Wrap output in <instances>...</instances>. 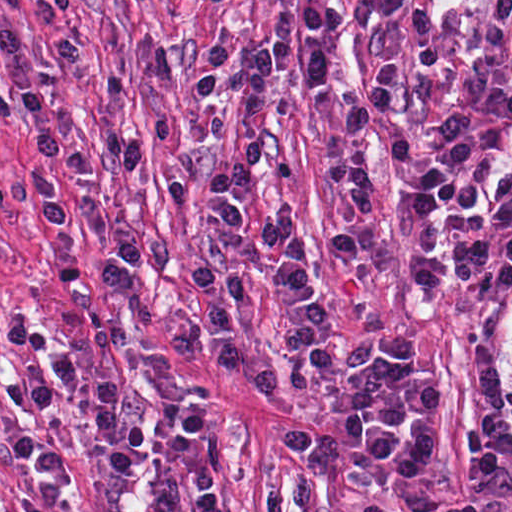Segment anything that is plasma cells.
<instances>
[{
  "label": "plasma cells",
  "mask_w": 512,
  "mask_h": 512,
  "mask_svg": "<svg viewBox=\"0 0 512 512\" xmlns=\"http://www.w3.org/2000/svg\"><path fill=\"white\" fill-rule=\"evenodd\" d=\"M413 0H342L368 55V69L335 108L336 137L352 151L378 130L403 80L395 51ZM295 58L312 86L323 88L335 65L317 38L257 47L233 82L239 157L207 183L200 203L211 230L207 257L236 261L278 291L288 309L282 346L310 369L304 395L334 375L336 438L312 434L291 412L280 371L244 328L262 301L247 276L193 267L198 309L168 328L173 354L201 358L272 399L278 439L290 461L264 488V512H315L325 477L357 451L383 461L405 483H426L434 377L408 361L403 331L358 329L340 362V339L305 259L291 207L279 205L256 228L242 203L262 158L254 140L268 113L278 67ZM384 230L406 293L445 315L477 318L505 304L512 281V0H489L456 49L454 78L416 136L387 166ZM469 426L458 457L470 480L512 485V363L502 382L491 341L465 338ZM512 512V511H510Z\"/></svg>",
  "instance_id": "plasma-cells-1"
}]
</instances>
